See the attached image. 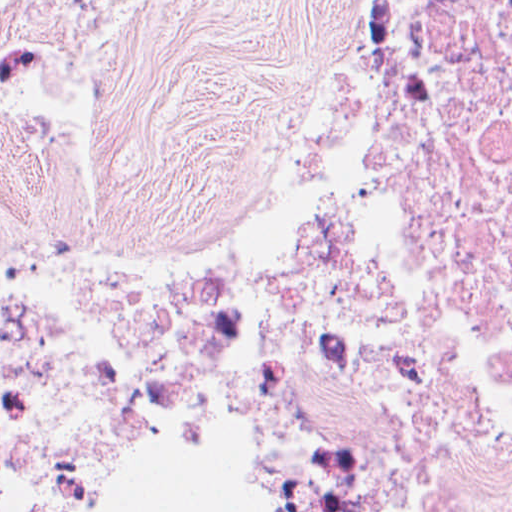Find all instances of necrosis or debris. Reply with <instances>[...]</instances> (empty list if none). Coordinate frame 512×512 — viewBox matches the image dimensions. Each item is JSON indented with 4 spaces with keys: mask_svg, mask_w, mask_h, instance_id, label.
Here are the masks:
<instances>
[{
    "mask_svg": "<svg viewBox=\"0 0 512 512\" xmlns=\"http://www.w3.org/2000/svg\"><path fill=\"white\" fill-rule=\"evenodd\" d=\"M124 0H0V446L68 362H112L215 431L255 512H512V0H349L249 258L182 284L40 268L73 124ZM0 512H103L98 396Z\"/></svg>",
    "mask_w": 512,
    "mask_h": 512,
    "instance_id": "4bbe7bcc",
    "label": "necrosis or debris"
}]
</instances>
